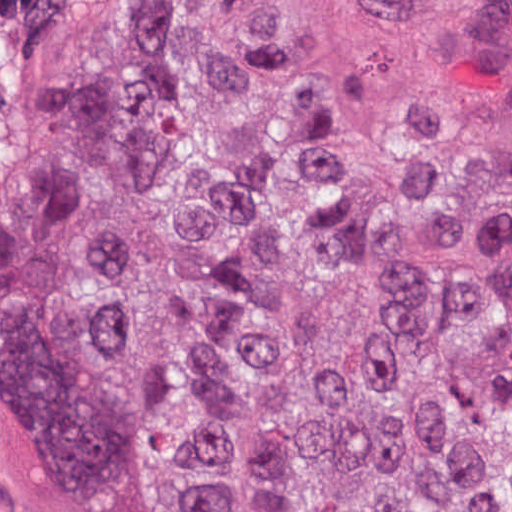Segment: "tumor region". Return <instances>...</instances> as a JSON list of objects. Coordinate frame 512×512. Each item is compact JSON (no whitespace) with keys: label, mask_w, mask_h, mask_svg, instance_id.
<instances>
[{"label":"tumor region","mask_w":512,"mask_h":512,"mask_svg":"<svg viewBox=\"0 0 512 512\" xmlns=\"http://www.w3.org/2000/svg\"><path fill=\"white\" fill-rule=\"evenodd\" d=\"M0 386L73 512H512V0H0Z\"/></svg>","instance_id":"e687c5a6"}]
</instances>
